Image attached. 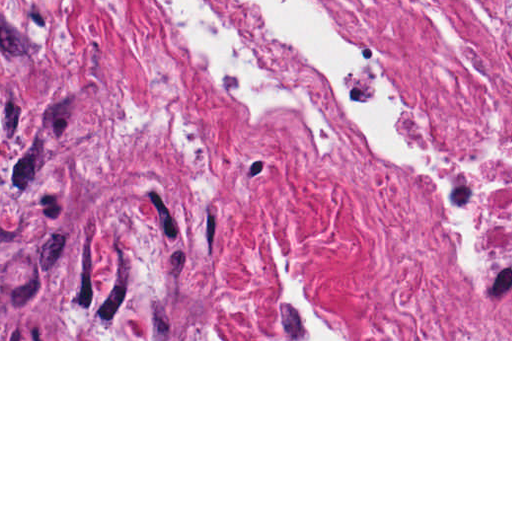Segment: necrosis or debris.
Here are the masks:
<instances>
[{"label": "necrosis or debris", "instance_id": "necrosis-or-debris-1", "mask_svg": "<svg viewBox=\"0 0 512 512\" xmlns=\"http://www.w3.org/2000/svg\"><path fill=\"white\" fill-rule=\"evenodd\" d=\"M256 208L354 202L403 339H512V0H143Z\"/></svg>", "mask_w": 512, "mask_h": 512}]
</instances>
